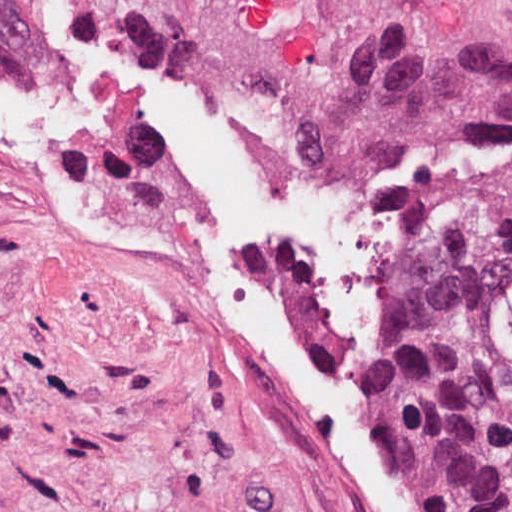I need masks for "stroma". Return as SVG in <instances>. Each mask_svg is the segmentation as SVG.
Instances as JSON below:
<instances>
[{
    "label": "stroma",
    "instance_id": "35a3bbf8",
    "mask_svg": "<svg viewBox=\"0 0 512 512\" xmlns=\"http://www.w3.org/2000/svg\"><path fill=\"white\" fill-rule=\"evenodd\" d=\"M25 5L40 56L42 0ZM91 5L137 51L267 98L304 158L512 153V0ZM505 302L512 331V276ZM0 512H349L292 393L200 291L44 224L2 162Z\"/></svg>",
    "mask_w": 512,
    "mask_h": 512
}]
</instances>
